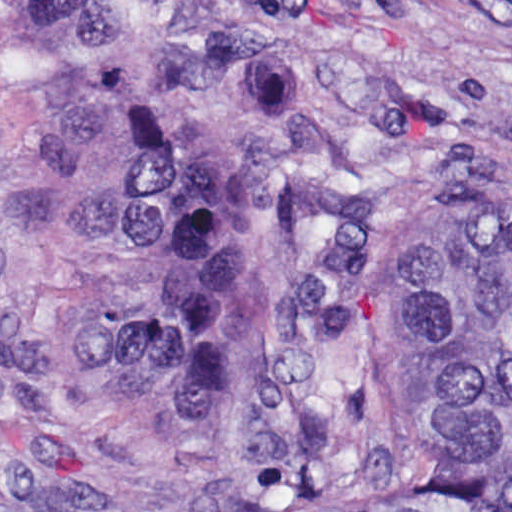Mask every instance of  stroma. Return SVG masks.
Instances as JSON below:
<instances>
[{"label": "stroma", "instance_id": "stroma-1", "mask_svg": "<svg viewBox=\"0 0 512 512\" xmlns=\"http://www.w3.org/2000/svg\"><path fill=\"white\" fill-rule=\"evenodd\" d=\"M308 2L313 52L375 86L361 144L379 177L327 454L405 482L419 434L391 340L412 254L512 223V0ZM92 93L80 49L39 44L0 0V512H301L258 489L244 450L93 377Z\"/></svg>", "mask_w": 512, "mask_h": 512}]
</instances>
